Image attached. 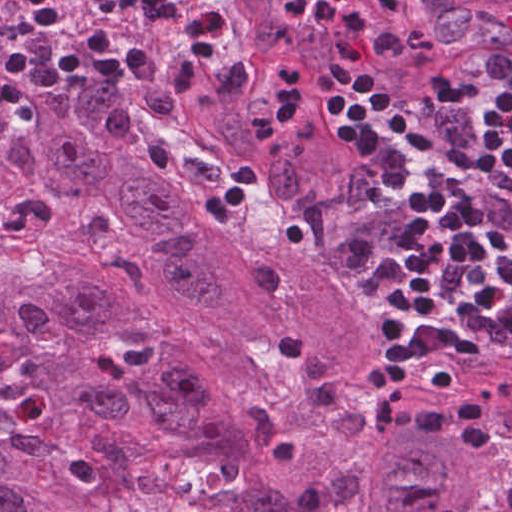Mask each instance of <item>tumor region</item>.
I'll use <instances>...</instances> for the list:
<instances>
[{"label":"tumor region","instance_id":"tumor-region-1","mask_svg":"<svg viewBox=\"0 0 512 512\" xmlns=\"http://www.w3.org/2000/svg\"><path fill=\"white\" fill-rule=\"evenodd\" d=\"M0 0V56L21 31ZM208 53L146 16L148 83L73 79L51 115L0 110V512H166L147 473L170 454L225 472L215 512H512V366L421 359L405 403L479 395L492 446L378 427V329L355 305L339 233L363 178L325 101L260 146L281 65L328 70L327 34L282 0H218ZM369 29L364 95L430 100L512 55V0L439 27L399 0H337ZM53 44L134 33L108 0H61ZM255 182L224 225L203 206L236 167Z\"/></svg>","mask_w":512,"mask_h":512}]
</instances>
